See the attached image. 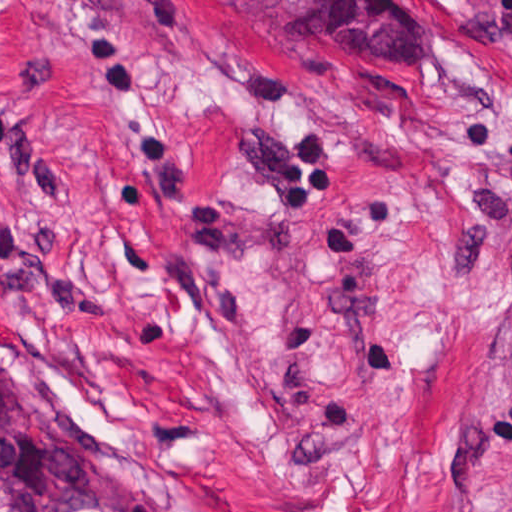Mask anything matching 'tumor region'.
<instances>
[{"instance_id":"e687c5a6","label":"tumor region","mask_w":512,"mask_h":512,"mask_svg":"<svg viewBox=\"0 0 512 512\" xmlns=\"http://www.w3.org/2000/svg\"><path fill=\"white\" fill-rule=\"evenodd\" d=\"M0 512H178L142 480L94 462L65 426L0 367Z\"/></svg>"}]
</instances>
